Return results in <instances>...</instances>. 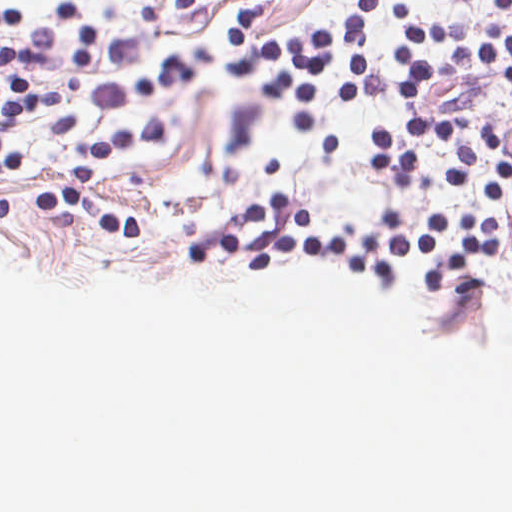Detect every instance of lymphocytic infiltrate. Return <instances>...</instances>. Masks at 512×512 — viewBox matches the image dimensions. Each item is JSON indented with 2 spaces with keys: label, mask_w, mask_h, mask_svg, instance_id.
Wrapping results in <instances>:
<instances>
[{
  "label": "lymphocytic infiltrate",
  "mask_w": 512,
  "mask_h": 512,
  "mask_svg": "<svg viewBox=\"0 0 512 512\" xmlns=\"http://www.w3.org/2000/svg\"><path fill=\"white\" fill-rule=\"evenodd\" d=\"M400 32L390 51L408 65L394 78L404 101H418L427 84L445 77L506 75L512 80V35L506 13L512 0H498L500 14L455 23L422 21L398 0ZM373 15V0H357L346 21L307 35L247 39L248 5L237 3L224 19L227 44L257 61L265 80L340 105H362L367 97L363 34ZM395 123L512 161V132L490 125L465 138L461 118L416 114Z\"/></svg>",
  "instance_id": "lymphocytic-infiltrate-1"
}]
</instances>
